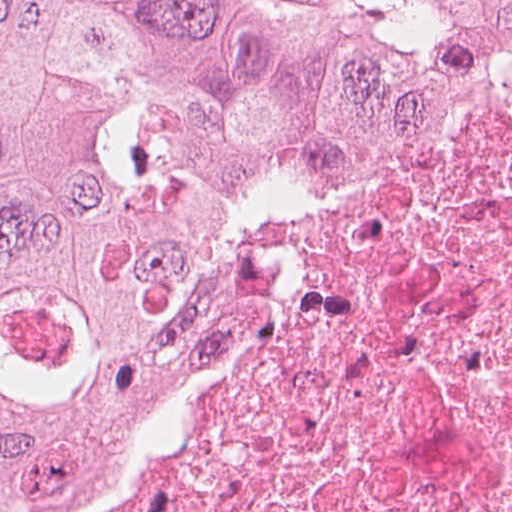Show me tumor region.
Here are the masks:
<instances>
[{"label":"tumor region","mask_w":512,"mask_h":512,"mask_svg":"<svg viewBox=\"0 0 512 512\" xmlns=\"http://www.w3.org/2000/svg\"><path fill=\"white\" fill-rule=\"evenodd\" d=\"M512 54V0H0V512L194 400L264 176Z\"/></svg>","instance_id":"e687c5a6"}]
</instances>
